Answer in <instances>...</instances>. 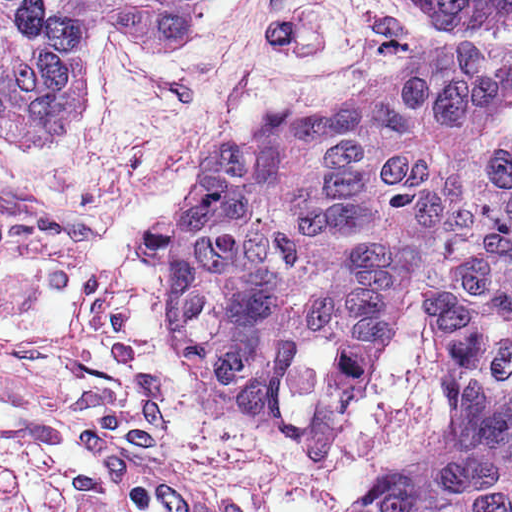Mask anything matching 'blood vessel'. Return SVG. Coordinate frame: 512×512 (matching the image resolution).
I'll return each instance as SVG.
<instances>
[{"mask_svg":"<svg viewBox=\"0 0 512 512\" xmlns=\"http://www.w3.org/2000/svg\"><path fill=\"white\" fill-rule=\"evenodd\" d=\"M78 447L112 512H233L211 472L164 439H149L93 412H75Z\"/></svg>","mask_w":512,"mask_h":512,"instance_id":"blood-vessel-1","label":"blood vessel"}]
</instances>
